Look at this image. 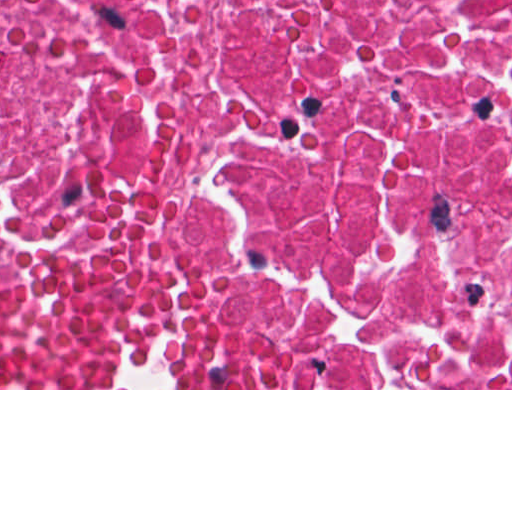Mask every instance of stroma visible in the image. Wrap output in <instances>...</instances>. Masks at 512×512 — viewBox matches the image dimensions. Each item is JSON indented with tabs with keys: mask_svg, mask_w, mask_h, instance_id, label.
Returning <instances> with one entry per match:
<instances>
[{
	"mask_svg": "<svg viewBox=\"0 0 512 512\" xmlns=\"http://www.w3.org/2000/svg\"><path fill=\"white\" fill-rule=\"evenodd\" d=\"M89 253H111L139 258L136 252L103 238L68 259L44 278L0 280V306L54 300L68 289ZM0 390H512V388H0Z\"/></svg>",
	"mask_w": 512,
	"mask_h": 512,
	"instance_id": "stroma-1",
	"label": "stroma"
}]
</instances>
